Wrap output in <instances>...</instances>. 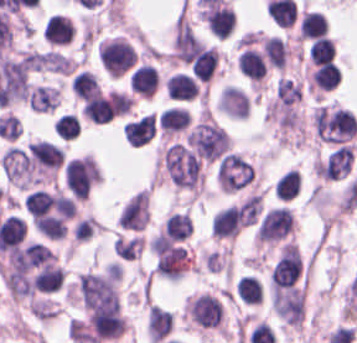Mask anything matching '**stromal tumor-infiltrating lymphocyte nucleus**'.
Masks as SVG:
<instances>
[{"mask_svg":"<svg viewBox=\"0 0 357 343\" xmlns=\"http://www.w3.org/2000/svg\"><path fill=\"white\" fill-rule=\"evenodd\" d=\"M202 17L215 38H229L235 22L234 11L225 4L209 1Z\"/></svg>","mask_w":357,"mask_h":343,"instance_id":"obj_1","label":"stromal tumor-infiltrating lymphocyte nucleus"},{"mask_svg":"<svg viewBox=\"0 0 357 343\" xmlns=\"http://www.w3.org/2000/svg\"><path fill=\"white\" fill-rule=\"evenodd\" d=\"M240 229V214L237 205H230L214 214L212 234L218 239H235Z\"/></svg>","mask_w":357,"mask_h":343,"instance_id":"obj_2","label":"stromal tumor-infiltrating lymphocyte nucleus"},{"mask_svg":"<svg viewBox=\"0 0 357 343\" xmlns=\"http://www.w3.org/2000/svg\"><path fill=\"white\" fill-rule=\"evenodd\" d=\"M166 88L169 96L178 101L194 100L198 91V83L188 73L176 72L167 81Z\"/></svg>","mask_w":357,"mask_h":343,"instance_id":"obj_3","label":"stromal tumor-infiltrating lymphocyte nucleus"},{"mask_svg":"<svg viewBox=\"0 0 357 343\" xmlns=\"http://www.w3.org/2000/svg\"><path fill=\"white\" fill-rule=\"evenodd\" d=\"M191 116L183 106H169L162 111L158 123L166 136H171L188 127Z\"/></svg>","mask_w":357,"mask_h":343,"instance_id":"obj_4","label":"stromal tumor-infiltrating lymphocyte nucleus"},{"mask_svg":"<svg viewBox=\"0 0 357 343\" xmlns=\"http://www.w3.org/2000/svg\"><path fill=\"white\" fill-rule=\"evenodd\" d=\"M158 83L157 70L149 64L138 66L130 75V88L140 96H153Z\"/></svg>","mask_w":357,"mask_h":343,"instance_id":"obj_5","label":"stromal tumor-infiltrating lymphocyte nucleus"},{"mask_svg":"<svg viewBox=\"0 0 357 343\" xmlns=\"http://www.w3.org/2000/svg\"><path fill=\"white\" fill-rule=\"evenodd\" d=\"M236 64L239 70L251 81H262L266 72V64L257 50L246 47L240 53Z\"/></svg>","mask_w":357,"mask_h":343,"instance_id":"obj_6","label":"stromal tumor-infiltrating lymphocyte nucleus"},{"mask_svg":"<svg viewBox=\"0 0 357 343\" xmlns=\"http://www.w3.org/2000/svg\"><path fill=\"white\" fill-rule=\"evenodd\" d=\"M218 50L215 48H199L189 62L194 79L208 81L215 67Z\"/></svg>","mask_w":357,"mask_h":343,"instance_id":"obj_7","label":"stromal tumor-infiltrating lymphocyte nucleus"},{"mask_svg":"<svg viewBox=\"0 0 357 343\" xmlns=\"http://www.w3.org/2000/svg\"><path fill=\"white\" fill-rule=\"evenodd\" d=\"M328 27L322 12L305 11L299 23L297 40H311L324 36Z\"/></svg>","mask_w":357,"mask_h":343,"instance_id":"obj_8","label":"stromal tumor-infiltrating lymphocyte nucleus"},{"mask_svg":"<svg viewBox=\"0 0 357 343\" xmlns=\"http://www.w3.org/2000/svg\"><path fill=\"white\" fill-rule=\"evenodd\" d=\"M47 43L65 45L72 39V24L64 16L52 14L45 22Z\"/></svg>","mask_w":357,"mask_h":343,"instance_id":"obj_9","label":"stromal tumor-infiltrating lymphocyte nucleus"},{"mask_svg":"<svg viewBox=\"0 0 357 343\" xmlns=\"http://www.w3.org/2000/svg\"><path fill=\"white\" fill-rule=\"evenodd\" d=\"M342 79V71L333 63L319 65L312 74V82L319 90H333Z\"/></svg>","mask_w":357,"mask_h":343,"instance_id":"obj_10","label":"stromal tumor-infiltrating lymphocyte nucleus"},{"mask_svg":"<svg viewBox=\"0 0 357 343\" xmlns=\"http://www.w3.org/2000/svg\"><path fill=\"white\" fill-rule=\"evenodd\" d=\"M240 300L246 304H260L263 290L257 279L252 275H245L235 284Z\"/></svg>","mask_w":357,"mask_h":343,"instance_id":"obj_11","label":"stromal tumor-infiltrating lymphocyte nucleus"},{"mask_svg":"<svg viewBox=\"0 0 357 343\" xmlns=\"http://www.w3.org/2000/svg\"><path fill=\"white\" fill-rule=\"evenodd\" d=\"M301 183L296 169H288L275 183V195L282 200H292L297 196Z\"/></svg>","mask_w":357,"mask_h":343,"instance_id":"obj_12","label":"stromal tumor-infiltrating lymphocyte nucleus"},{"mask_svg":"<svg viewBox=\"0 0 357 343\" xmlns=\"http://www.w3.org/2000/svg\"><path fill=\"white\" fill-rule=\"evenodd\" d=\"M53 129L63 141H71L81 132V122L77 115L64 113L55 123Z\"/></svg>","mask_w":357,"mask_h":343,"instance_id":"obj_13","label":"stromal tumor-infiltrating lymphocyte nucleus"},{"mask_svg":"<svg viewBox=\"0 0 357 343\" xmlns=\"http://www.w3.org/2000/svg\"><path fill=\"white\" fill-rule=\"evenodd\" d=\"M308 52L312 64L323 65L330 61L334 55V44L325 37H318L313 40Z\"/></svg>","mask_w":357,"mask_h":343,"instance_id":"obj_14","label":"stromal tumor-infiltrating lymphocyte nucleus"}]
</instances>
